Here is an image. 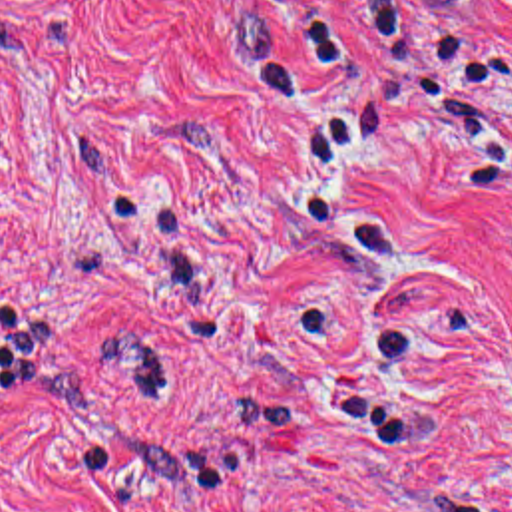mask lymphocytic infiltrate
<instances>
[{
    "label": "lymphocytic infiltrate",
    "mask_w": 512,
    "mask_h": 512,
    "mask_svg": "<svg viewBox=\"0 0 512 512\" xmlns=\"http://www.w3.org/2000/svg\"><path fill=\"white\" fill-rule=\"evenodd\" d=\"M239 1L259 49L293 77L362 43L398 0Z\"/></svg>",
    "instance_id": "f902f5d3"
}]
</instances>
